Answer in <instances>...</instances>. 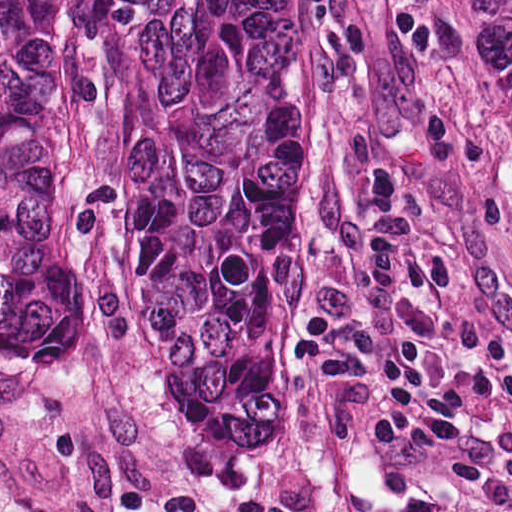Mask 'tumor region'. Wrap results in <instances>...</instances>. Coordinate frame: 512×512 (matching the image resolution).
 I'll return each instance as SVG.
<instances>
[{
  "mask_svg": "<svg viewBox=\"0 0 512 512\" xmlns=\"http://www.w3.org/2000/svg\"><path fill=\"white\" fill-rule=\"evenodd\" d=\"M512 167V0H450ZM320 175L309 0H0V355L233 451Z\"/></svg>",
  "mask_w": 512,
  "mask_h": 512,
  "instance_id": "e687c5a6",
  "label": "tumor region"
}]
</instances>
